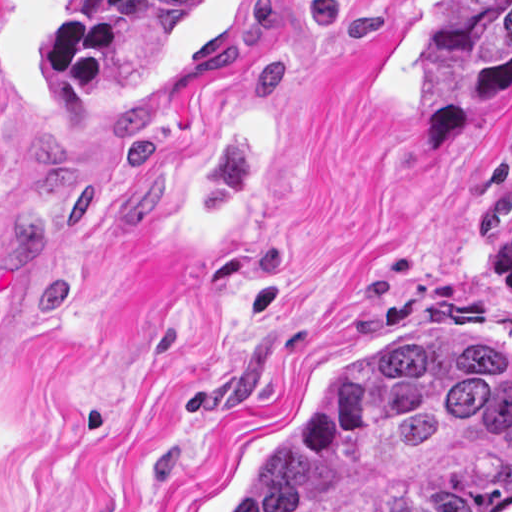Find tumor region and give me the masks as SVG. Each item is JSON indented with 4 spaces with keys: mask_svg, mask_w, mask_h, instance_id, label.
<instances>
[{
    "mask_svg": "<svg viewBox=\"0 0 512 512\" xmlns=\"http://www.w3.org/2000/svg\"><path fill=\"white\" fill-rule=\"evenodd\" d=\"M207 0H76L46 74L77 110L139 78ZM512 0H432L427 125L480 141L511 108ZM484 241L512 291V184L487 205ZM512 363L454 348L361 352L308 426L225 512H510Z\"/></svg>",
    "mask_w": 512,
    "mask_h": 512,
    "instance_id": "1",
    "label": "tumor region"
}]
</instances>
